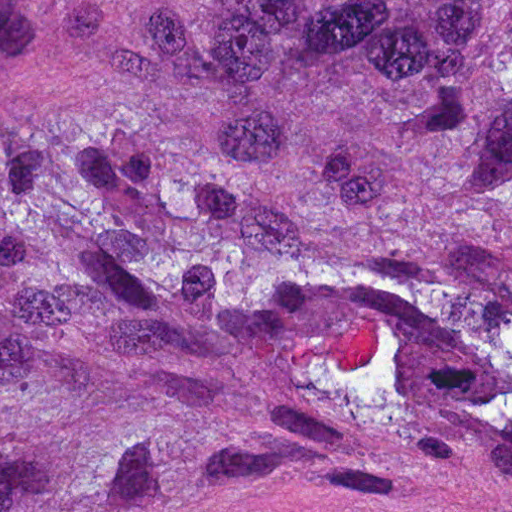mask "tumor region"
Returning <instances> with one entry per match:
<instances>
[{"mask_svg": "<svg viewBox=\"0 0 512 512\" xmlns=\"http://www.w3.org/2000/svg\"><path fill=\"white\" fill-rule=\"evenodd\" d=\"M0 512H512V0H0Z\"/></svg>", "mask_w": 512, "mask_h": 512, "instance_id": "1", "label": "tumor region"}]
</instances>
